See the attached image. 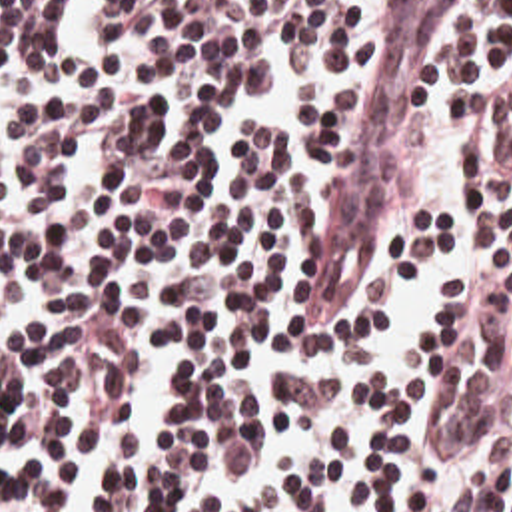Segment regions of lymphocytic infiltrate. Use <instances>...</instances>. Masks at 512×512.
<instances>
[{
    "label": "lymphocytic infiltrate",
    "instance_id": "obj_1",
    "mask_svg": "<svg viewBox=\"0 0 512 512\" xmlns=\"http://www.w3.org/2000/svg\"><path fill=\"white\" fill-rule=\"evenodd\" d=\"M361 7L0 0V512H512V0L429 83L469 277L397 383L271 369L373 357L455 235L397 197L291 321Z\"/></svg>",
    "mask_w": 512,
    "mask_h": 512
}]
</instances>
